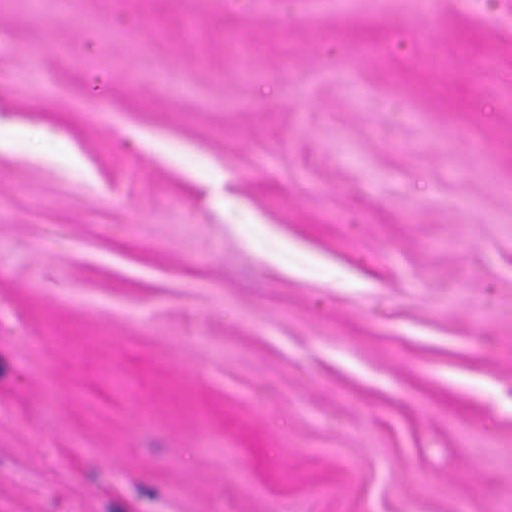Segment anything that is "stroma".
<instances>
[{"instance_id": "obj_1", "label": "stroma", "mask_w": 512, "mask_h": 512, "mask_svg": "<svg viewBox=\"0 0 512 512\" xmlns=\"http://www.w3.org/2000/svg\"><path fill=\"white\" fill-rule=\"evenodd\" d=\"M0 512H512V0H0Z\"/></svg>"}]
</instances>
